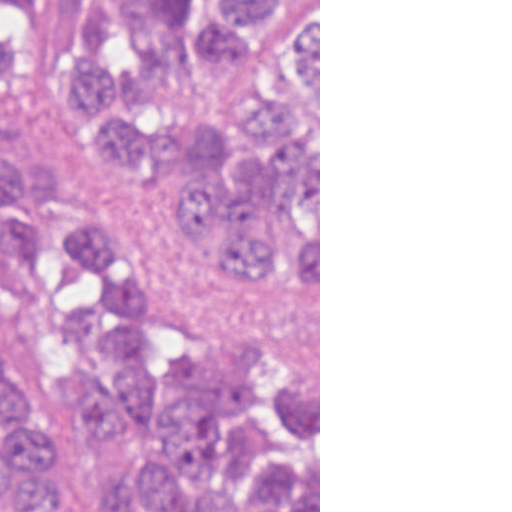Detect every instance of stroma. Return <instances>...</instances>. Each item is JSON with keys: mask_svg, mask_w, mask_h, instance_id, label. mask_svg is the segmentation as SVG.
Returning a JSON list of instances; mask_svg holds the SVG:
<instances>
[{"mask_svg": "<svg viewBox=\"0 0 512 512\" xmlns=\"http://www.w3.org/2000/svg\"><path fill=\"white\" fill-rule=\"evenodd\" d=\"M15 157L32 174L51 164L70 192L88 198L137 243L174 303L210 313H254L282 325L319 369L320 512V0H319V304H273L216 278L221 264L166 223L132 175L91 158V141L63 104L35 80L0 87V163Z\"/></svg>", "mask_w": 512, "mask_h": 512, "instance_id": "1", "label": "stroma"}]
</instances>
